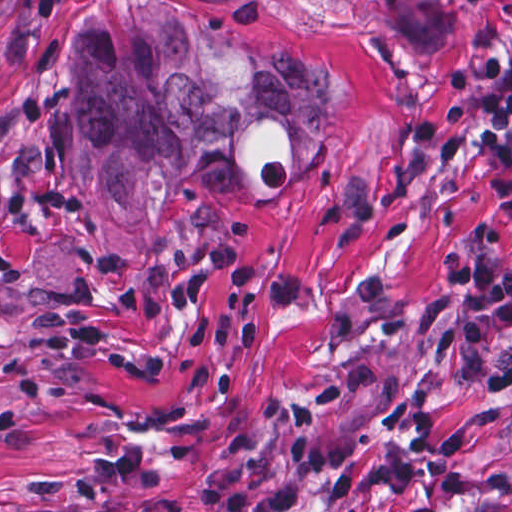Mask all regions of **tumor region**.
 Returning a JSON list of instances; mask_svg holds the SVG:
<instances>
[{
  "instance_id": "e687c5a6",
  "label": "tumor region",
  "mask_w": 512,
  "mask_h": 512,
  "mask_svg": "<svg viewBox=\"0 0 512 512\" xmlns=\"http://www.w3.org/2000/svg\"><path fill=\"white\" fill-rule=\"evenodd\" d=\"M327 147V83L188 4L94 0L0 107V321L88 302L100 274L160 259L171 194H262Z\"/></svg>"
}]
</instances>
